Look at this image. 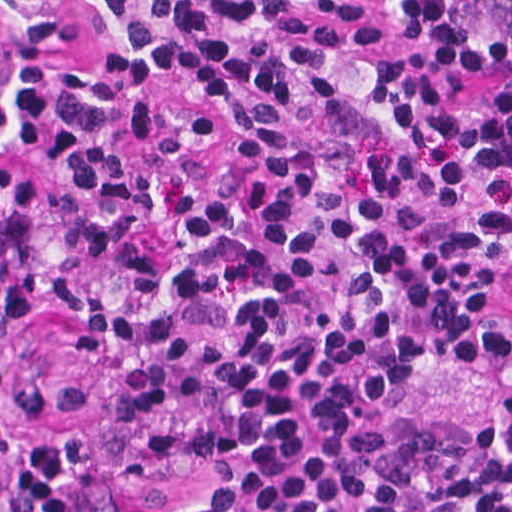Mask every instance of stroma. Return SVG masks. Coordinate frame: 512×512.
<instances>
[{"label":"stroma","mask_w":512,"mask_h":512,"mask_svg":"<svg viewBox=\"0 0 512 512\" xmlns=\"http://www.w3.org/2000/svg\"><path fill=\"white\" fill-rule=\"evenodd\" d=\"M1 290V271H0ZM494 313L512 335V272L494 285ZM79 336L73 317L55 307L9 317L0 307V353L9 378L19 383H55L82 396L81 414L25 423L19 435L42 439L73 434L99 449L98 465L73 491L81 512H171L202 477H158L130 482L108 463V431L102 414L106 382L98 364L74 353ZM512 384V351L487 368L437 361L415 384L385 407L386 419L404 422H461L479 413L494 388Z\"/></svg>","instance_id":"1"}]
</instances>
